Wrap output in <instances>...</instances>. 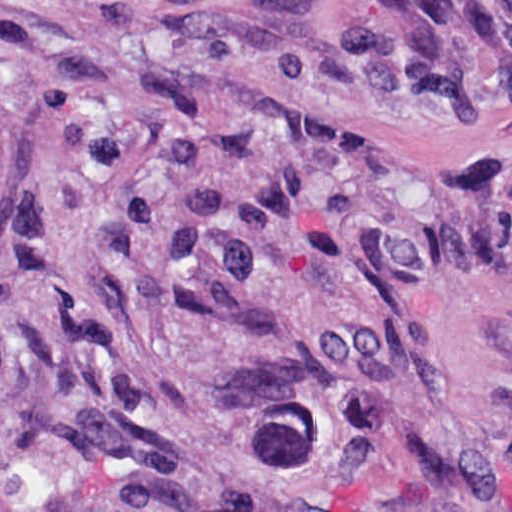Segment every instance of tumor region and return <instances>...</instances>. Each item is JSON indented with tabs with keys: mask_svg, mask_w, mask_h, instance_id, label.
I'll return each instance as SVG.
<instances>
[{
	"mask_svg": "<svg viewBox=\"0 0 512 512\" xmlns=\"http://www.w3.org/2000/svg\"><path fill=\"white\" fill-rule=\"evenodd\" d=\"M365 74L401 95H477L510 80L512 1H381L366 24ZM32 191L18 200L0 97V218Z\"/></svg>",
	"mask_w": 512,
	"mask_h": 512,
	"instance_id": "obj_1",
	"label": "tumor region"
}]
</instances>
